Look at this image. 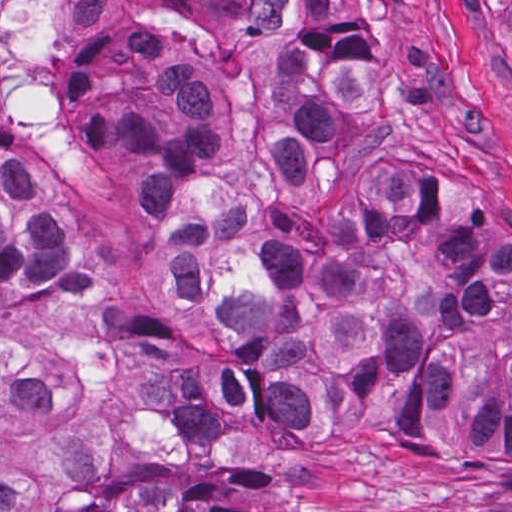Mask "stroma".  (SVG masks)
<instances>
[{
    "mask_svg": "<svg viewBox=\"0 0 512 512\" xmlns=\"http://www.w3.org/2000/svg\"><path fill=\"white\" fill-rule=\"evenodd\" d=\"M371 37L368 83L387 141L410 151L428 194L473 212L512 252V55L473 0H336ZM79 0H6L0 95L13 137L68 42ZM245 0H93L69 40L62 153L0 144V168L67 193L66 217L100 299L134 329L179 339L213 363L235 355L151 264L132 227L140 182L114 130L109 83L133 48L199 59L215 109L247 114L257 68ZM30 349L49 394L110 429L124 476L201 471L252 512H512V466L433 469L394 446L395 424L352 414L316 435L247 424L158 435L131 404L126 360L80 358L15 332L0 298V350Z\"/></svg>",
    "mask_w": 512,
    "mask_h": 512,
    "instance_id": "stroma-1",
    "label": "stroma"
}]
</instances>
